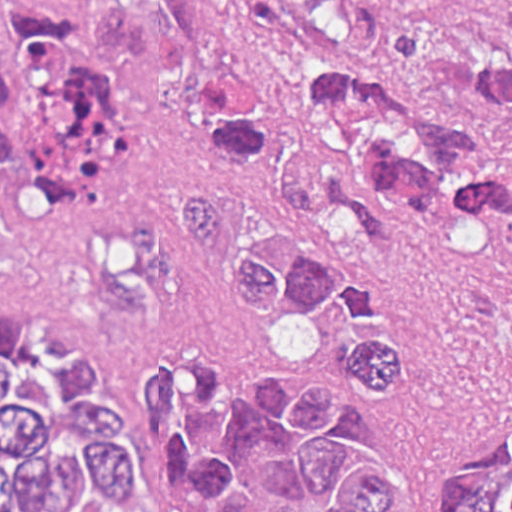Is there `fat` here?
Masks as SVG:
<instances>
[{
  "instance_id": "53f6f03d",
  "label": "fat",
  "mask_w": 512,
  "mask_h": 512,
  "mask_svg": "<svg viewBox=\"0 0 512 512\" xmlns=\"http://www.w3.org/2000/svg\"><path fill=\"white\" fill-rule=\"evenodd\" d=\"M306 319L295 316L272 325L266 338L274 360L286 366H309L316 359V336L305 325Z\"/></svg>"
}]
</instances>
